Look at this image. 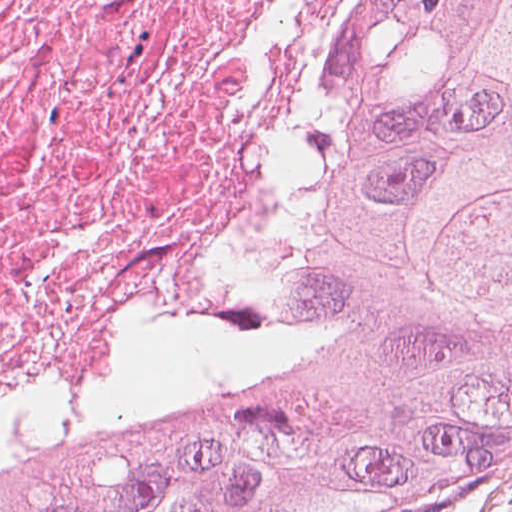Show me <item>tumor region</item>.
I'll return each instance as SVG.
<instances>
[{
  "instance_id": "tumor-region-1",
  "label": "tumor region",
  "mask_w": 512,
  "mask_h": 512,
  "mask_svg": "<svg viewBox=\"0 0 512 512\" xmlns=\"http://www.w3.org/2000/svg\"><path fill=\"white\" fill-rule=\"evenodd\" d=\"M512 489V0H395L277 294L0 512H392Z\"/></svg>"
}]
</instances>
